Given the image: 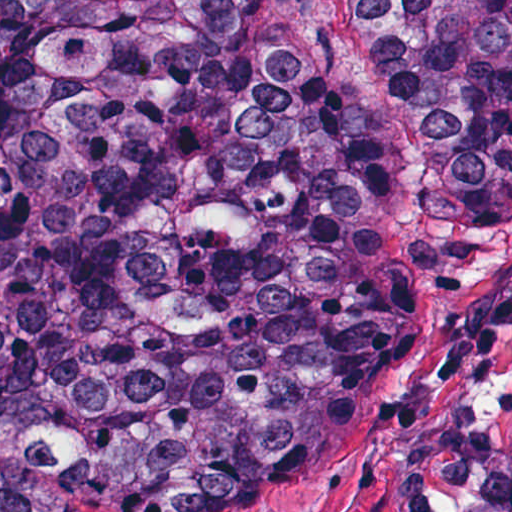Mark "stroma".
<instances>
[{
    "instance_id": "obj_1",
    "label": "stroma",
    "mask_w": 512,
    "mask_h": 512,
    "mask_svg": "<svg viewBox=\"0 0 512 512\" xmlns=\"http://www.w3.org/2000/svg\"><path fill=\"white\" fill-rule=\"evenodd\" d=\"M315 21L341 102L400 171L418 272L407 348L340 462H167L117 512H512V177L442 220L419 190L415 129L363 63L349 0H315Z\"/></svg>"
}]
</instances>
